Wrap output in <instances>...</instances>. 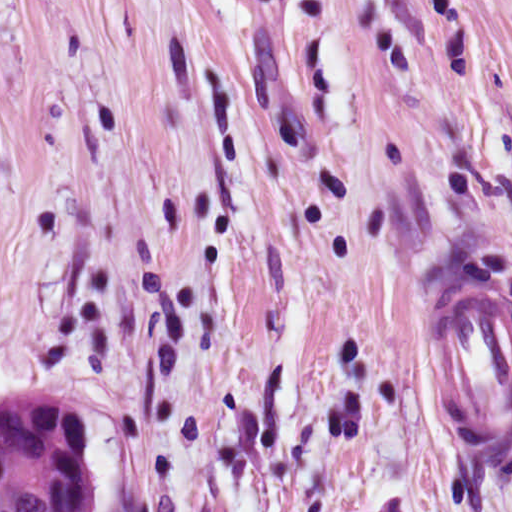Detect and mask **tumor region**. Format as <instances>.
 I'll return each instance as SVG.
<instances>
[{
    "label": "tumor region",
    "mask_w": 512,
    "mask_h": 512,
    "mask_svg": "<svg viewBox=\"0 0 512 512\" xmlns=\"http://www.w3.org/2000/svg\"><path fill=\"white\" fill-rule=\"evenodd\" d=\"M98 471L80 414L43 381L0 388V512H97Z\"/></svg>",
    "instance_id": "1"
}]
</instances>
